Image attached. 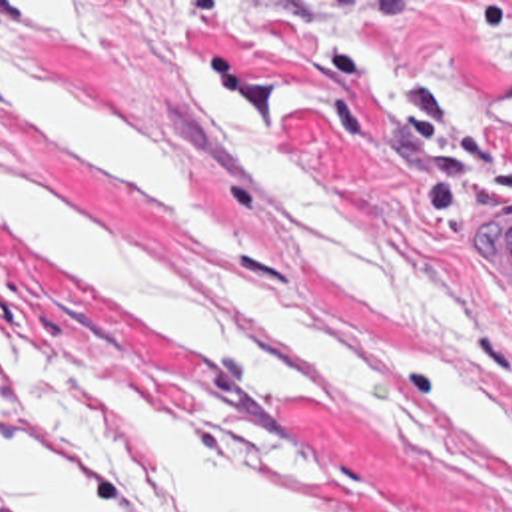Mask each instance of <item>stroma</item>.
<instances>
[{
    "instance_id": "35a3bbf8",
    "label": "stroma",
    "mask_w": 512,
    "mask_h": 512,
    "mask_svg": "<svg viewBox=\"0 0 512 512\" xmlns=\"http://www.w3.org/2000/svg\"><path fill=\"white\" fill-rule=\"evenodd\" d=\"M0 64L173 148L235 224L207 268L0 136L71 214L281 331L309 385L279 415L41 288L0 226V343L81 359L159 421L339 512H512V475L437 435L389 337H423L512 399V294L485 228L512 220V0H0Z\"/></svg>"
}]
</instances>
